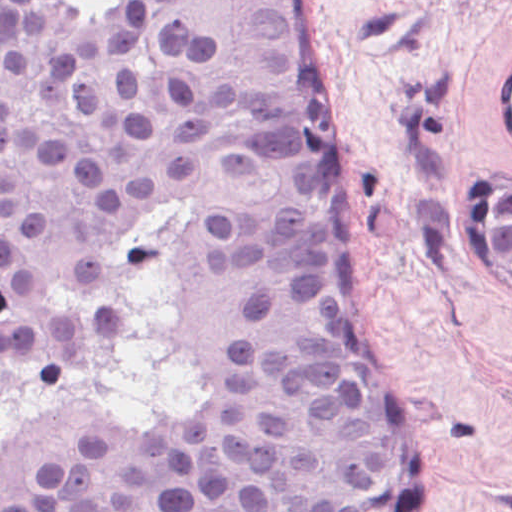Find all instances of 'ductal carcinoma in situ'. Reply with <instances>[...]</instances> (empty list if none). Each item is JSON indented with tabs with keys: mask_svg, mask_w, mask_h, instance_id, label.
<instances>
[{
	"mask_svg": "<svg viewBox=\"0 0 512 512\" xmlns=\"http://www.w3.org/2000/svg\"><path fill=\"white\" fill-rule=\"evenodd\" d=\"M312 0H0V512H431Z\"/></svg>",
	"mask_w": 512,
	"mask_h": 512,
	"instance_id": "ductal-carcinoma-in-situ-1",
	"label": "ductal carcinoma in situ"
}]
</instances>
